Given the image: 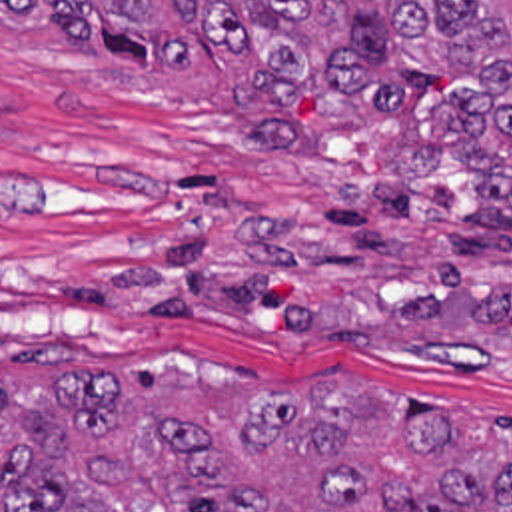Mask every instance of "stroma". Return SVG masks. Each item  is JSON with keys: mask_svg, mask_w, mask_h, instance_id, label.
Returning <instances> with one entry per match:
<instances>
[{"mask_svg": "<svg viewBox=\"0 0 512 512\" xmlns=\"http://www.w3.org/2000/svg\"><path fill=\"white\" fill-rule=\"evenodd\" d=\"M247 60L138 74L60 32L0 30V338L42 376L200 387L371 383L512 425V234L477 230L475 170L413 230L363 190L389 124L255 152Z\"/></svg>", "mask_w": 512, "mask_h": 512, "instance_id": "stroma-1", "label": "stroma"}]
</instances>
